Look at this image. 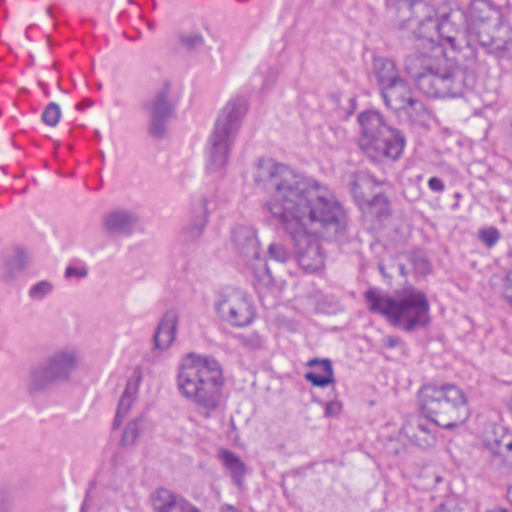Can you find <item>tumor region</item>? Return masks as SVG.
Returning <instances> with one entry per match:
<instances>
[{"mask_svg": "<svg viewBox=\"0 0 512 512\" xmlns=\"http://www.w3.org/2000/svg\"><path fill=\"white\" fill-rule=\"evenodd\" d=\"M409 38L413 54H394L382 74L393 90L358 109L359 187L335 188L284 152L265 182L276 231L231 223L237 264L210 290L206 331L236 357L197 349L174 374V397L217 465L225 506L212 512H257L248 397L301 377L309 338L346 327L371 335L423 418L477 440L504 474L496 494H437L421 512H512V378L497 414L479 412L418 358L426 319L446 315L512 366V93L450 156L430 124L441 102L481 96L489 75L512 70V1L429 0ZM147 512L205 511L158 474Z\"/></svg>", "mask_w": 512, "mask_h": 512, "instance_id": "tumor-region-1", "label": "tumor region"}]
</instances>
